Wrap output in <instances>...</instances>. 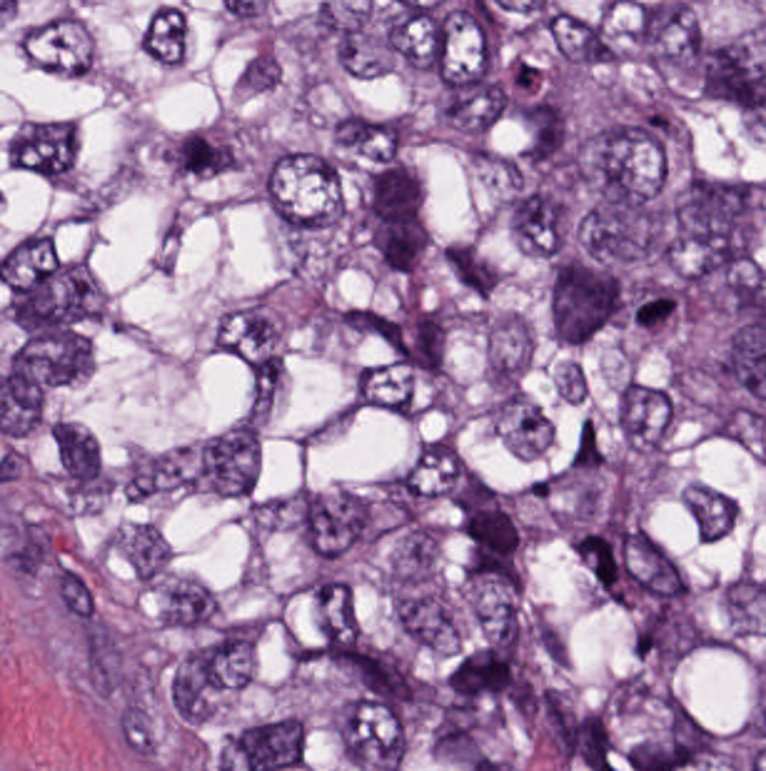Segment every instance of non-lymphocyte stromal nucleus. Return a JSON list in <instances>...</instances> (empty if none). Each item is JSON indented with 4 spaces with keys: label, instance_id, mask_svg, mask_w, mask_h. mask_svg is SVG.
Instances as JSON below:
<instances>
[{
    "label": "non-lymphocyte stromal nucleus",
    "instance_id": "non-lymphocyte-stromal-nucleus-1",
    "mask_svg": "<svg viewBox=\"0 0 766 771\" xmlns=\"http://www.w3.org/2000/svg\"><path fill=\"white\" fill-rule=\"evenodd\" d=\"M56 614H97V563H56Z\"/></svg>",
    "mask_w": 766,
    "mask_h": 771
}]
</instances>
